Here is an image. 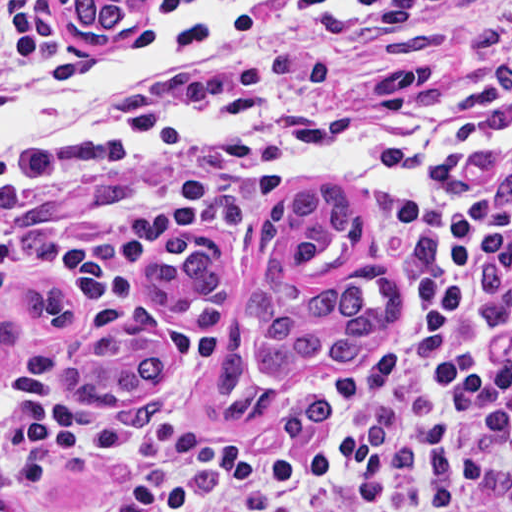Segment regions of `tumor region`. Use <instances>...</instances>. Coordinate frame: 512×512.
I'll return each instance as SVG.
<instances>
[{"label":"tumor region","instance_id":"e687c5a6","mask_svg":"<svg viewBox=\"0 0 512 512\" xmlns=\"http://www.w3.org/2000/svg\"><path fill=\"white\" fill-rule=\"evenodd\" d=\"M16 0H0L14 2ZM71 42L85 51H114L141 26L150 0H52ZM357 199L283 196L262 234L259 273L247 280L226 264L214 241L172 236L145 259L143 277L154 296L186 315L218 319L243 297L255 340L253 367L261 377L288 376L310 361L370 360L397 314V282L390 273L355 277L335 288L300 291L295 277L344 266L355 251ZM31 321L0 324V357L42 336L67 337L85 319V298L70 286L40 285L18 293ZM170 364V344L151 310L109 324L68 366L63 388L77 403L135 399L158 384ZM211 378L219 416L230 430L263 424L284 435H313L328 418L324 395H287L256 388L248 349L232 324L214 340Z\"/></svg>","mask_w":512,"mask_h":512}]
</instances>
